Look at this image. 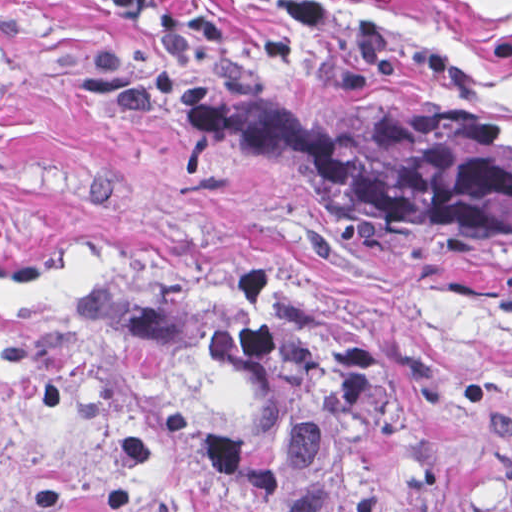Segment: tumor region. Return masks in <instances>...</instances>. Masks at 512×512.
<instances>
[{
    "instance_id": "1",
    "label": "tumor region",
    "mask_w": 512,
    "mask_h": 512,
    "mask_svg": "<svg viewBox=\"0 0 512 512\" xmlns=\"http://www.w3.org/2000/svg\"><path fill=\"white\" fill-rule=\"evenodd\" d=\"M206 145L274 186L512 247V97L326 72L200 90ZM83 299L141 317L258 437L196 436L246 512H506L413 391L325 312L268 284L135 272Z\"/></svg>"
}]
</instances>
